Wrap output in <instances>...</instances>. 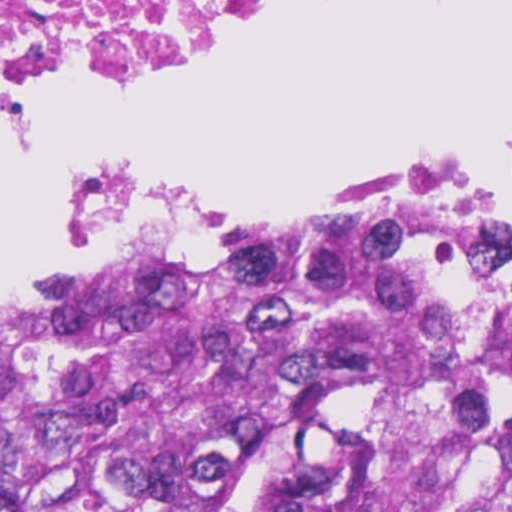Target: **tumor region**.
I'll list each match as a JSON object with an SVG mask.
<instances>
[{
	"instance_id": "e687c5a6",
	"label": "tumor region",
	"mask_w": 512,
	"mask_h": 512,
	"mask_svg": "<svg viewBox=\"0 0 512 512\" xmlns=\"http://www.w3.org/2000/svg\"><path fill=\"white\" fill-rule=\"evenodd\" d=\"M0 512H512V238L390 205L0 291Z\"/></svg>"
}]
</instances>
